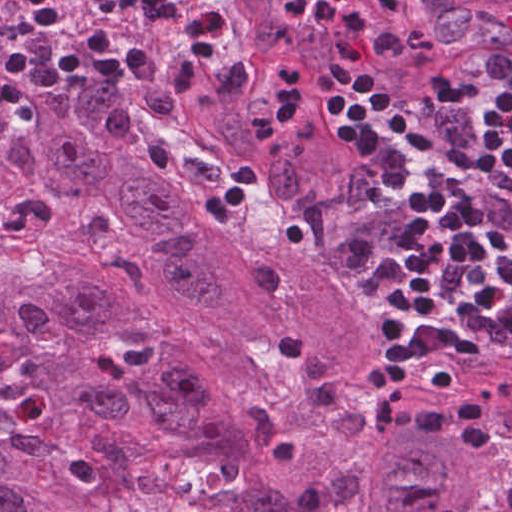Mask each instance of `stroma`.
<instances>
[{"label": "stroma", "instance_id": "stroma-1", "mask_svg": "<svg viewBox=\"0 0 512 512\" xmlns=\"http://www.w3.org/2000/svg\"><path fill=\"white\" fill-rule=\"evenodd\" d=\"M413 22L421 27H439L449 22L466 21L490 8L502 0H399ZM338 95L325 104L345 97ZM355 305L364 318L378 329V310L381 306L383 291L368 288L349 276ZM426 319L415 306L409 315L406 328L412 331ZM469 360L489 362L469 349Z\"/></svg>", "mask_w": 512, "mask_h": 512}]
</instances>
